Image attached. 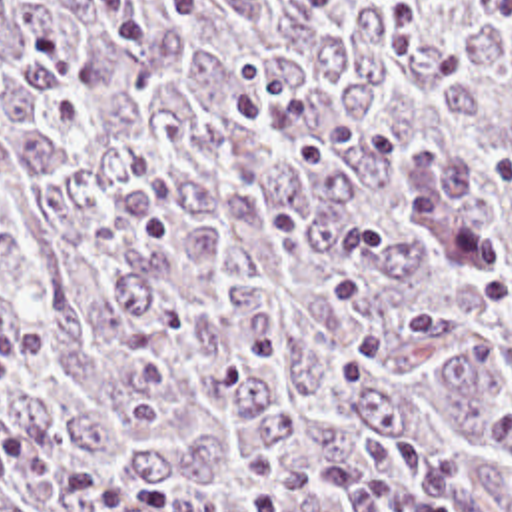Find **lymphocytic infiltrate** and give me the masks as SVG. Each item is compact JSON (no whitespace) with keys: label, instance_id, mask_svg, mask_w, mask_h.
<instances>
[{"label":"lymphocytic infiltrate","instance_id":"obj_1","mask_svg":"<svg viewBox=\"0 0 512 512\" xmlns=\"http://www.w3.org/2000/svg\"><path fill=\"white\" fill-rule=\"evenodd\" d=\"M37 352L31 322L0 326V462L25 476L56 512H170L176 496L162 480L136 476L108 464L84 460L58 444H31L19 438L3 416V388L9 372ZM406 512H446L422 504Z\"/></svg>","mask_w":512,"mask_h":512}]
</instances>
